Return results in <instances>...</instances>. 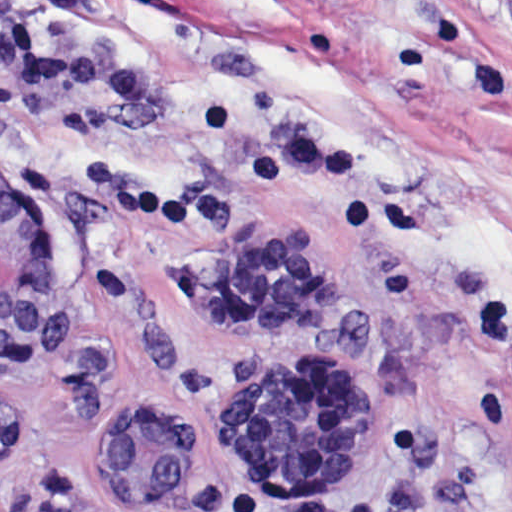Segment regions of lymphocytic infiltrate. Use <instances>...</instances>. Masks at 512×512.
Returning a JSON list of instances; mask_svg holds the SVG:
<instances>
[{
	"label": "lymphocytic infiltrate",
	"instance_id": "lymphocytic-infiltrate-1",
	"mask_svg": "<svg viewBox=\"0 0 512 512\" xmlns=\"http://www.w3.org/2000/svg\"><path fill=\"white\" fill-rule=\"evenodd\" d=\"M0 68L33 91L78 90L135 106L151 104V82L136 70L59 59L29 35L15 0H0ZM481 333L495 366L477 416L491 433L512 420V306L500 295L481 307Z\"/></svg>",
	"mask_w": 512,
	"mask_h": 512
}]
</instances>
